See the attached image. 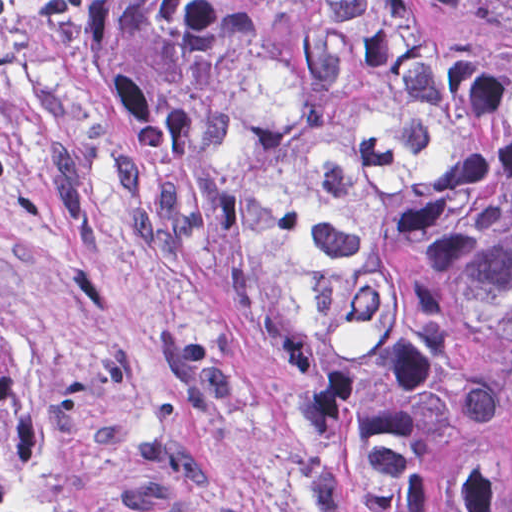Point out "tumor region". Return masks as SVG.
<instances>
[{
  "instance_id": "obj_1",
  "label": "tumor region",
  "mask_w": 512,
  "mask_h": 512,
  "mask_svg": "<svg viewBox=\"0 0 512 512\" xmlns=\"http://www.w3.org/2000/svg\"><path fill=\"white\" fill-rule=\"evenodd\" d=\"M91 67L294 349L311 512H512V24L423 0H101ZM0 512H129L0 328Z\"/></svg>"
}]
</instances>
